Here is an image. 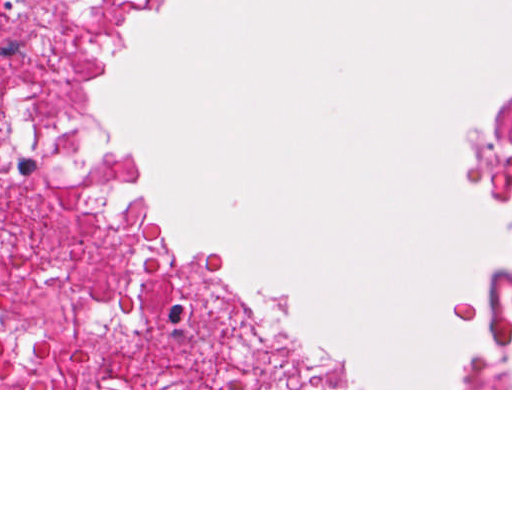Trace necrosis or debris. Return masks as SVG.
Returning <instances> with one entry per match:
<instances>
[{
    "label": "necrosis or debris",
    "mask_w": 512,
    "mask_h": 512,
    "mask_svg": "<svg viewBox=\"0 0 512 512\" xmlns=\"http://www.w3.org/2000/svg\"><path fill=\"white\" fill-rule=\"evenodd\" d=\"M89 0H0V388H268L175 327L89 147ZM507 192V267L467 388H512V106L475 139Z\"/></svg>",
    "instance_id": "necrosis-or-debris-1"
}]
</instances>
